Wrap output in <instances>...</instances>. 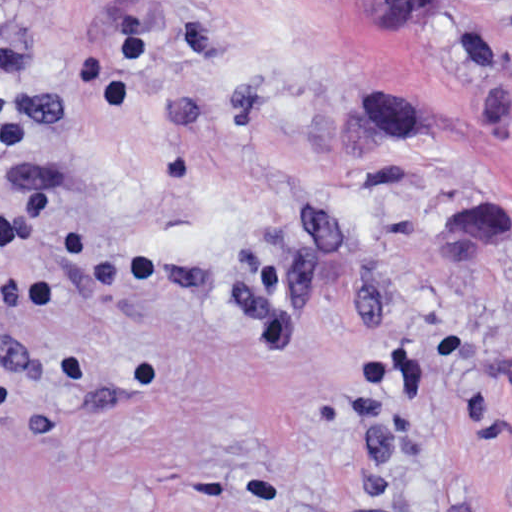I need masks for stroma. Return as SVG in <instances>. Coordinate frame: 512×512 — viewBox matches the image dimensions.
Instances as JSON below:
<instances>
[{
    "mask_svg": "<svg viewBox=\"0 0 512 512\" xmlns=\"http://www.w3.org/2000/svg\"><path fill=\"white\" fill-rule=\"evenodd\" d=\"M0 0V512H512V0Z\"/></svg>",
    "mask_w": 512,
    "mask_h": 512,
    "instance_id": "stroma-1",
    "label": "stroma"
}]
</instances>
